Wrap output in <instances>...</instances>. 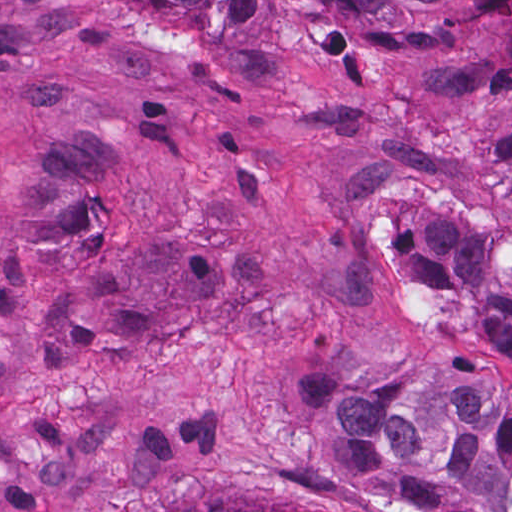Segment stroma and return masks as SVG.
Masks as SVG:
<instances>
[{"instance_id": "35a3bbf8", "label": "stroma", "mask_w": 512, "mask_h": 512, "mask_svg": "<svg viewBox=\"0 0 512 512\" xmlns=\"http://www.w3.org/2000/svg\"><path fill=\"white\" fill-rule=\"evenodd\" d=\"M289 1L278 39L0 0V512H390L314 466L283 362L398 361L390 201L460 204L512 83L430 99L455 32Z\"/></svg>"}]
</instances>
